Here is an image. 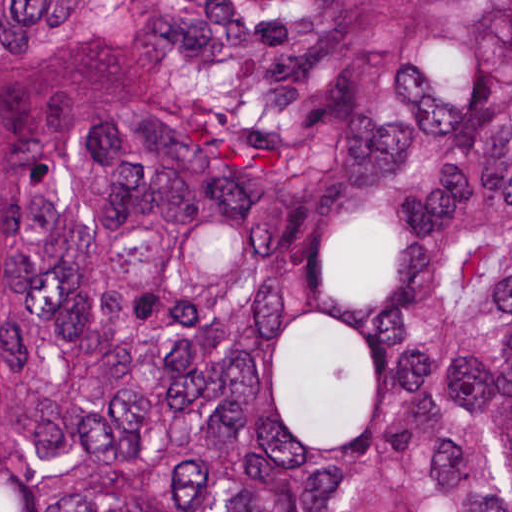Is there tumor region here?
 Listing matches in <instances>:
<instances>
[{"instance_id": "tumor-region-1", "label": "tumor region", "mask_w": 512, "mask_h": 512, "mask_svg": "<svg viewBox=\"0 0 512 512\" xmlns=\"http://www.w3.org/2000/svg\"><path fill=\"white\" fill-rule=\"evenodd\" d=\"M0 512H512V0H0Z\"/></svg>"}]
</instances>
